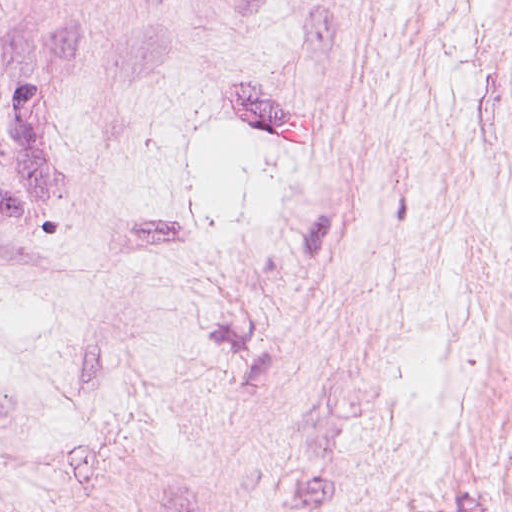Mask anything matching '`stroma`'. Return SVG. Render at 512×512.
Masks as SVG:
<instances>
[{
    "label": "stroma",
    "mask_w": 512,
    "mask_h": 512,
    "mask_svg": "<svg viewBox=\"0 0 512 512\" xmlns=\"http://www.w3.org/2000/svg\"><path fill=\"white\" fill-rule=\"evenodd\" d=\"M0 512H512V0H0Z\"/></svg>",
    "instance_id": "obj_1"
}]
</instances>
